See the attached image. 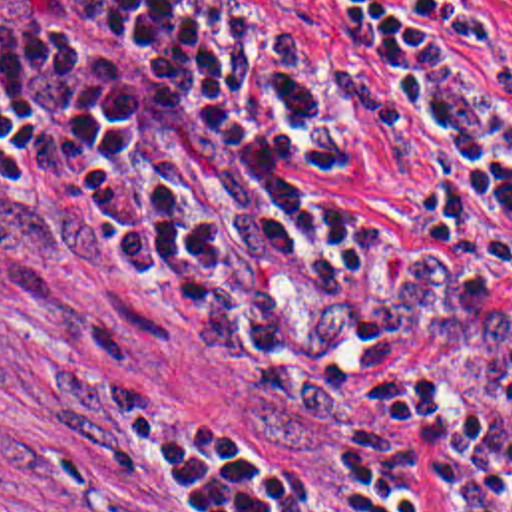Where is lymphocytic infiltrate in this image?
Returning a JSON list of instances; mask_svg holds the SVG:
<instances>
[{
	"instance_id": "f902f5d3",
	"label": "lymphocytic infiltrate",
	"mask_w": 512,
	"mask_h": 512,
	"mask_svg": "<svg viewBox=\"0 0 512 512\" xmlns=\"http://www.w3.org/2000/svg\"><path fill=\"white\" fill-rule=\"evenodd\" d=\"M0 0V254L80 268L250 385L224 512H512V57L463 0Z\"/></svg>"
}]
</instances>
